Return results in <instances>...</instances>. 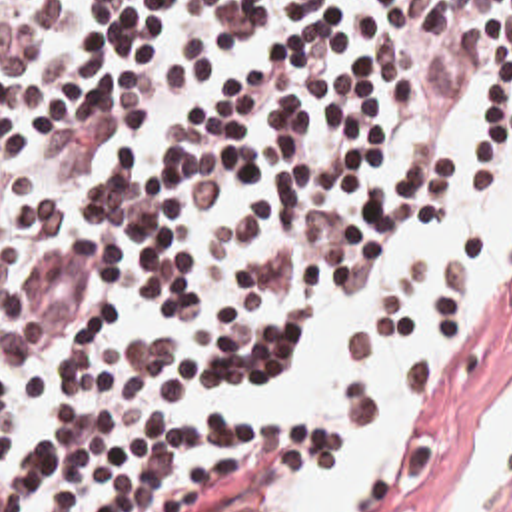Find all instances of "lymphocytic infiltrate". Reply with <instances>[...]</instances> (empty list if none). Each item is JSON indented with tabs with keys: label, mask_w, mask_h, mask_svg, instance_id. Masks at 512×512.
Masks as SVG:
<instances>
[{
	"label": "lymphocytic infiltrate",
	"mask_w": 512,
	"mask_h": 512,
	"mask_svg": "<svg viewBox=\"0 0 512 512\" xmlns=\"http://www.w3.org/2000/svg\"><path fill=\"white\" fill-rule=\"evenodd\" d=\"M481 76L489 190L512 0H0V512H295L309 448L245 388L457 218ZM487 244L349 352L437 326Z\"/></svg>",
	"instance_id": "1"
}]
</instances>
